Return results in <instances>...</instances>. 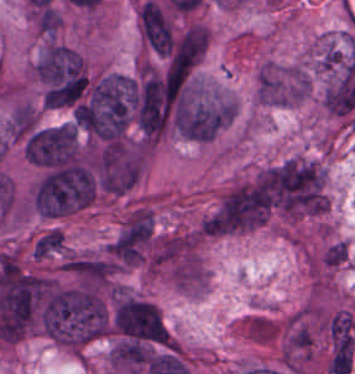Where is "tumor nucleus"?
I'll return each mask as SVG.
<instances>
[{"instance_id":"obj_1","label":"tumor nucleus","mask_w":355,"mask_h":374,"mask_svg":"<svg viewBox=\"0 0 355 374\" xmlns=\"http://www.w3.org/2000/svg\"><path fill=\"white\" fill-rule=\"evenodd\" d=\"M77 125H45L31 130L25 146L26 156L39 166H58L77 156Z\"/></svg>"},{"instance_id":"obj_2","label":"tumor nucleus","mask_w":355,"mask_h":374,"mask_svg":"<svg viewBox=\"0 0 355 374\" xmlns=\"http://www.w3.org/2000/svg\"><path fill=\"white\" fill-rule=\"evenodd\" d=\"M36 120V109L26 102L14 105L5 130L14 137H22L31 131Z\"/></svg>"},{"instance_id":"obj_3","label":"tumor nucleus","mask_w":355,"mask_h":374,"mask_svg":"<svg viewBox=\"0 0 355 374\" xmlns=\"http://www.w3.org/2000/svg\"><path fill=\"white\" fill-rule=\"evenodd\" d=\"M64 249L63 235L56 229H49L36 239L31 254L35 260H42Z\"/></svg>"},{"instance_id":"obj_4","label":"tumor nucleus","mask_w":355,"mask_h":374,"mask_svg":"<svg viewBox=\"0 0 355 374\" xmlns=\"http://www.w3.org/2000/svg\"><path fill=\"white\" fill-rule=\"evenodd\" d=\"M324 264L330 266L342 265L347 259V244L343 240H336L329 245L322 255Z\"/></svg>"}]
</instances>
